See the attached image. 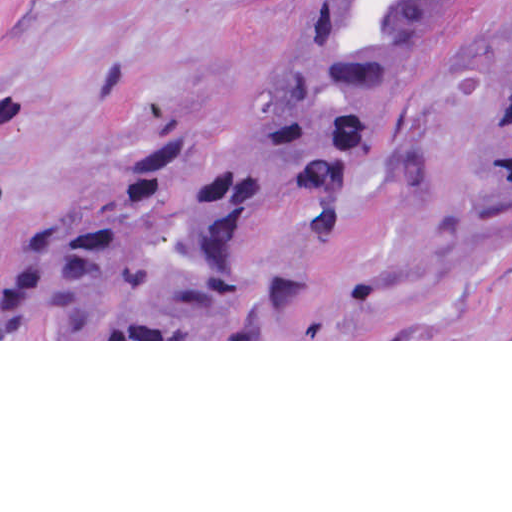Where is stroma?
I'll list each match as a JSON object with an SVG mask.
<instances>
[{
    "label": "stroma",
    "mask_w": 512,
    "mask_h": 512,
    "mask_svg": "<svg viewBox=\"0 0 512 512\" xmlns=\"http://www.w3.org/2000/svg\"><path fill=\"white\" fill-rule=\"evenodd\" d=\"M317 0H0V252L93 165L167 127L198 165L242 127ZM512 71V0H432L350 200L276 231L293 305L231 336H153L10 282L0 341H512V211L472 200L471 142Z\"/></svg>",
    "instance_id": "35a3bbf8"
}]
</instances>
